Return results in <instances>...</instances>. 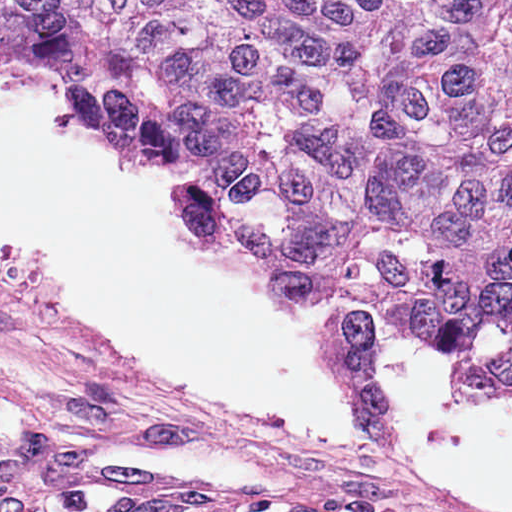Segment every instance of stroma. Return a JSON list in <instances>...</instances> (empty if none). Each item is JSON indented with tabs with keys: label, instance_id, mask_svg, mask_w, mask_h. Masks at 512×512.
Listing matches in <instances>:
<instances>
[{
	"label": "stroma",
	"instance_id": "stroma-1",
	"mask_svg": "<svg viewBox=\"0 0 512 512\" xmlns=\"http://www.w3.org/2000/svg\"><path fill=\"white\" fill-rule=\"evenodd\" d=\"M54 64L73 108L81 114L67 91L60 64ZM107 138L137 161L183 178L179 168L159 164ZM209 220L244 253L214 223L212 205ZM384 332L388 331L377 330L373 340ZM212 418L253 512H449L391 485L334 475L245 425Z\"/></svg>",
	"mask_w": 512,
	"mask_h": 512
}]
</instances>
